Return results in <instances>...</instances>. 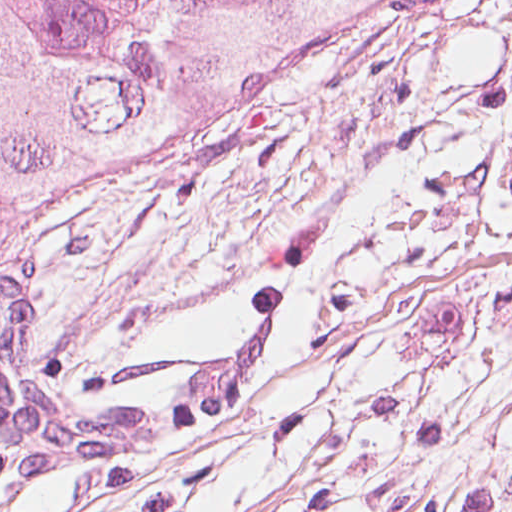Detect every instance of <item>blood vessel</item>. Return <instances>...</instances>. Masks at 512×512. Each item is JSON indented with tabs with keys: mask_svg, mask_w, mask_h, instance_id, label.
Masks as SVG:
<instances>
[{
	"mask_svg": "<svg viewBox=\"0 0 512 512\" xmlns=\"http://www.w3.org/2000/svg\"><path fill=\"white\" fill-rule=\"evenodd\" d=\"M281 306L241 339L199 360L188 381L148 401L78 405L38 374L35 318L24 276L0 315V439L27 470H81L173 438L249 393L280 327Z\"/></svg>",
	"mask_w": 512,
	"mask_h": 512,
	"instance_id": "blood-vessel-1",
	"label": "blood vessel"
}]
</instances>
